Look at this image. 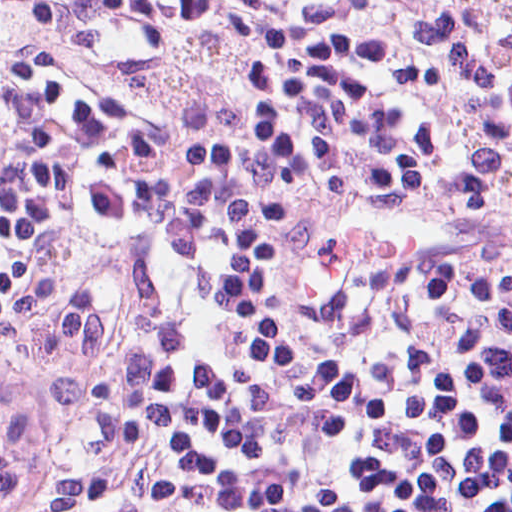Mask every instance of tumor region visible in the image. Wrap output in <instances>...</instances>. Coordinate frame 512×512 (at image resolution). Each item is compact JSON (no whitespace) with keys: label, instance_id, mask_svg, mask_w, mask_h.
Wrapping results in <instances>:
<instances>
[{"label":"tumor region","instance_id":"e687c5a6","mask_svg":"<svg viewBox=\"0 0 512 512\" xmlns=\"http://www.w3.org/2000/svg\"><path fill=\"white\" fill-rule=\"evenodd\" d=\"M26 412V387L0 373V469L11 456Z\"/></svg>","mask_w":512,"mask_h":512}]
</instances>
